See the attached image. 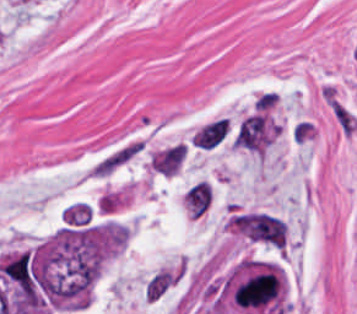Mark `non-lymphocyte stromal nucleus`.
Masks as SVG:
<instances>
[{"label":"non-lymphocyte stromal nucleus","mask_w":357,"mask_h":314,"mask_svg":"<svg viewBox=\"0 0 357 314\" xmlns=\"http://www.w3.org/2000/svg\"><path fill=\"white\" fill-rule=\"evenodd\" d=\"M186 152L185 144L174 143L155 154L149 162L160 173L174 175L180 169Z\"/></svg>","instance_id":"obj_5"},{"label":"non-lymphocyte stromal nucleus","mask_w":357,"mask_h":314,"mask_svg":"<svg viewBox=\"0 0 357 314\" xmlns=\"http://www.w3.org/2000/svg\"><path fill=\"white\" fill-rule=\"evenodd\" d=\"M213 198L210 183L207 179H200L185 192V204L193 216H200L205 212Z\"/></svg>","instance_id":"obj_6"},{"label":"non-lymphocyte stromal nucleus","mask_w":357,"mask_h":314,"mask_svg":"<svg viewBox=\"0 0 357 314\" xmlns=\"http://www.w3.org/2000/svg\"><path fill=\"white\" fill-rule=\"evenodd\" d=\"M324 99L341 133L352 136L357 130V114L332 85H325Z\"/></svg>","instance_id":"obj_4"},{"label":"non-lymphocyte stromal nucleus","mask_w":357,"mask_h":314,"mask_svg":"<svg viewBox=\"0 0 357 314\" xmlns=\"http://www.w3.org/2000/svg\"><path fill=\"white\" fill-rule=\"evenodd\" d=\"M142 151V140L130 139L114 146L91 166L93 175L106 177Z\"/></svg>","instance_id":"obj_2"},{"label":"non-lymphocyte stromal nucleus","mask_w":357,"mask_h":314,"mask_svg":"<svg viewBox=\"0 0 357 314\" xmlns=\"http://www.w3.org/2000/svg\"><path fill=\"white\" fill-rule=\"evenodd\" d=\"M229 118L220 117L198 129L193 139L197 144L211 146L223 139L228 132Z\"/></svg>","instance_id":"obj_7"},{"label":"non-lymphocyte stromal nucleus","mask_w":357,"mask_h":314,"mask_svg":"<svg viewBox=\"0 0 357 314\" xmlns=\"http://www.w3.org/2000/svg\"><path fill=\"white\" fill-rule=\"evenodd\" d=\"M186 271L187 263L181 259L153 271L143 285L144 297L153 302L163 298L183 279Z\"/></svg>","instance_id":"obj_1"},{"label":"non-lymphocyte stromal nucleus","mask_w":357,"mask_h":314,"mask_svg":"<svg viewBox=\"0 0 357 314\" xmlns=\"http://www.w3.org/2000/svg\"><path fill=\"white\" fill-rule=\"evenodd\" d=\"M235 140L236 144L240 146L262 152L269 145L267 115L255 113L244 119Z\"/></svg>","instance_id":"obj_3"}]
</instances>
